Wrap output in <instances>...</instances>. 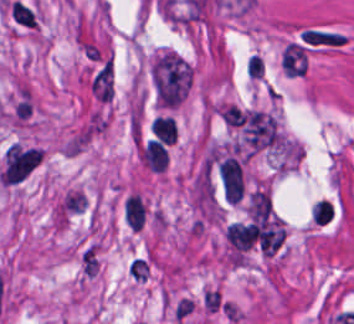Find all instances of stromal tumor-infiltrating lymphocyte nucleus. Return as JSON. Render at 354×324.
Listing matches in <instances>:
<instances>
[{"instance_id": "2", "label": "stromal tumor-infiltrating lymphocyte nucleus", "mask_w": 354, "mask_h": 324, "mask_svg": "<svg viewBox=\"0 0 354 324\" xmlns=\"http://www.w3.org/2000/svg\"><path fill=\"white\" fill-rule=\"evenodd\" d=\"M124 210L127 223L138 231L144 220V205L141 197L130 194L125 200Z\"/></svg>"}, {"instance_id": "5", "label": "stromal tumor-infiltrating lymphocyte nucleus", "mask_w": 354, "mask_h": 324, "mask_svg": "<svg viewBox=\"0 0 354 324\" xmlns=\"http://www.w3.org/2000/svg\"><path fill=\"white\" fill-rule=\"evenodd\" d=\"M332 214V206L326 200L315 202L311 209V218L324 224L330 222Z\"/></svg>"}, {"instance_id": "4", "label": "stromal tumor-infiltrating lymphocyte nucleus", "mask_w": 354, "mask_h": 324, "mask_svg": "<svg viewBox=\"0 0 354 324\" xmlns=\"http://www.w3.org/2000/svg\"><path fill=\"white\" fill-rule=\"evenodd\" d=\"M152 131L162 140H175V120L167 114H157L153 118Z\"/></svg>"}, {"instance_id": "1", "label": "stromal tumor-infiltrating lymphocyte nucleus", "mask_w": 354, "mask_h": 324, "mask_svg": "<svg viewBox=\"0 0 354 324\" xmlns=\"http://www.w3.org/2000/svg\"><path fill=\"white\" fill-rule=\"evenodd\" d=\"M142 156L150 169L163 170L168 152L162 140L148 138L143 150Z\"/></svg>"}, {"instance_id": "3", "label": "stromal tumor-infiltrating lymphocyte nucleus", "mask_w": 354, "mask_h": 324, "mask_svg": "<svg viewBox=\"0 0 354 324\" xmlns=\"http://www.w3.org/2000/svg\"><path fill=\"white\" fill-rule=\"evenodd\" d=\"M10 10L13 21L19 26L34 27L35 11L28 3L21 0H14Z\"/></svg>"}]
</instances>
